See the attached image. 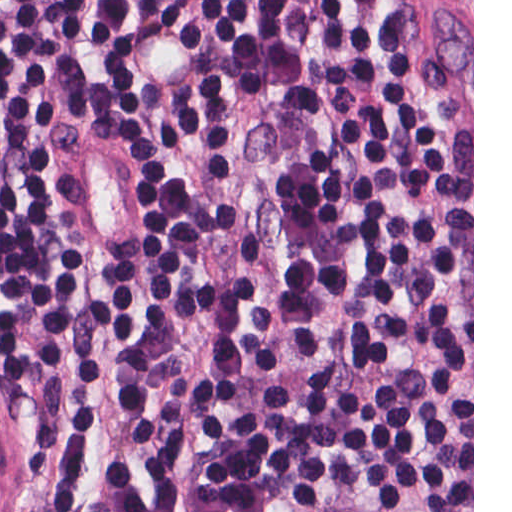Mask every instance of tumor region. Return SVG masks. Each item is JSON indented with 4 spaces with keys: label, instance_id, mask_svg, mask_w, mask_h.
Listing matches in <instances>:
<instances>
[{
    "label": "tumor region",
    "instance_id": "1",
    "mask_svg": "<svg viewBox=\"0 0 512 512\" xmlns=\"http://www.w3.org/2000/svg\"><path fill=\"white\" fill-rule=\"evenodd\" d=\"M460 26L472 44V0H454Z\"/></svg>",
    "mask_w": 512,
    "mask_h": 512
}]
</instances>
